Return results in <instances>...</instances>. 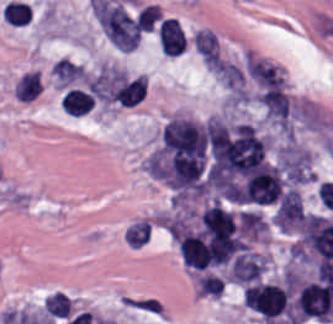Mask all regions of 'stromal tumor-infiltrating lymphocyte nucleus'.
Instances as JSON below:
<instances>
[{
  "instance_id": "obj_1",
  "label": "stromal tumor-infiltrating lymphocyte nucleus",
  "mask_w": 333,
  "mask_h": 324,
  "mask_svg": "<svg viewBox=\"0 0 333 324\" xmlns=\"http://www.w3.org/2000/svg\"><path fill=\"white\" fill-rule=\"evenodd\" d=\"M204 132L213 177L245 175L264 164V140L253 124L210 119Z\"/></svg>"
},
{
  "instance_id": "obj_2",
  "label": "stromal tumor-infiltrating lymphocyte nucleus",
  "mask_w": 333,
  "mask_h": 324,
  "mask_svg": "<svg viewBox=\"0 0 333 324\" xmlns=\"http://www.w3.org/2000/svg\"><path fill=\"white\" fill-rule=\"evenodd\" d=\"M205 136L191 117L174 115L163 125L159 153L202 165Z\"/></svg>"
},
{
  "instance_id": "obj_3",
  "label": "stromal tumor-infiltrating lymphocyte nucleus",
  "mask_w": 333,
  "mask_h": 324,
  "mask_svg": "<svg viewBox=\"0 0 333 324\" xmlns=\"http://www.w3.org/2000/svg\"><path fill=\"white\" fill-rule=\"evenodd\" d=\"M242 299L264 324H276L290 304L287 291L268 281H254L244 286Z\"/></svg>"
},
{
  "instance_id": "obj_4",
  "label": "stromal tumor-infiltrating lymphocyte nucleus",
  "mask_w": 333,
  "mask_h": 324,
  "mask_svg": "<svg viewBox=\"0 0 333 324\" xmlns=\"http://www.w3.org/2000/svg\"><path fill=\"white\" fill-rule=\"evenodd\" d=\"M158 40L164 55H179L183 52L186 39L177 18L165 17L159 22Z\"/></svg>"
},
{
  "instance_id": "obj_5",
  "label": "stromal tumor-infiltrating lymphocyte nucleus",
  "mask_w": 333,
  "mask_h": 324,
  "mask_svg": "<svg viewBox=\"0 0 333 324\" xmlns=\"http://www.w3.org/2000/svg\"><path fill=\"white\" fill-rule=\"evenodd\" d=\"M154 227L155 224L150 215L132 219L122 229V240L126 246L143 248L150 241Z\"/></svg>"
},
{
  "instance_id": "obj_6",
  "label": "stromal tumor-infiltrating lymphocyte nucleus",
  "mask_w": 333,
  "mask_h": 324,
  "mask_svg": "<svg viewBox=\"0 0 333 324\" xmlns=\"http://www.w3.org/2000/svg\"><path fill=\"white\" fill-rule=\"evenodd\" d=\"M94 100L81 87H68L61 99L60 106L69 114H84L88 111Z\"/></svg>"
},
{
  "instance_id": "obj_7",
  "label": "stromal tumor-infiltrating lymphocyte nucleus",
  "mask_w": 333,
  "mask_h": 324,
  "mask_svg": "<svg viewBox=\"0 0 333 324\" xmlns=\"http://www.w3.org/2000/svg\"><path fill=\"white\" fill-rule=\"evenodd\" d=\"M31 6L26 1L9 0L1 8V17L14 25L28 23Z\"/></svg>"
}]
</instances>
